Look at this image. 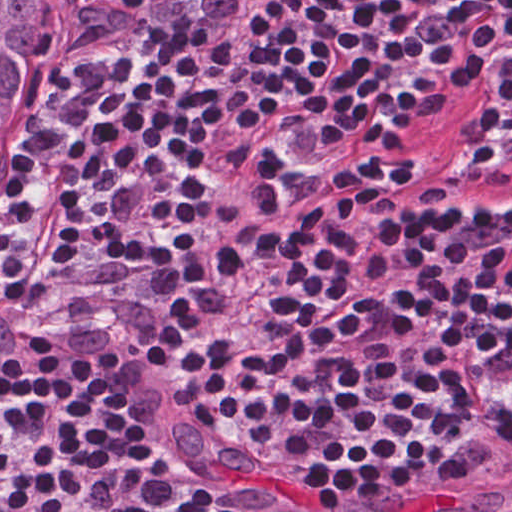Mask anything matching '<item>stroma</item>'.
Here are the masks:
<instances>
[{
  "label": "stroma",
  "mask_w": 512,
  "mask_h": 512,
  "mask_svg": "<svg viewBox=\"0 0 512 512\" xmlns=\"http://www.w3.org/2000/svg\"><path fill=\"white\" fill-rule=\"evenodd\" d=\"M43 75L48 76L56 85V114L61 105L59 38ZM28 272L31 275L29 269ZM43 291L79 332L101 365L114 377L129 404L151 420L207 452L223 470L236 475L247 487L265 496L280 510L333 512L353 503L329 506L308 495L278 459L280 450L256 449L233 439L218 420L195 410L166 384L147 372L78 316L57 303L45 290ZM428 477L404 471L390 486L354 502L416 485Z\"/></svg>",
  "instance_id": "obj_1"
}]
</instances>
